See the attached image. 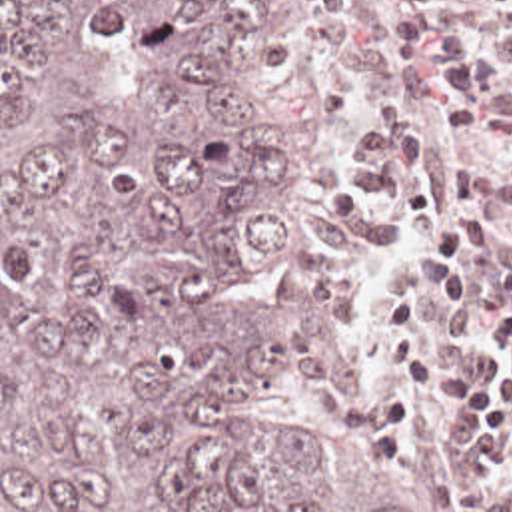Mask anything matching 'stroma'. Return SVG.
I'll return each instance as SVG.
<instances>
[{"label": "stroma", "instance_id": "obj_1", "mask_svg": "<svg viewBox=\"0 0 512 512\" xmlns=\"http://www.w3.org/2000/svg\"><path fill=\"white\" fill-rule=\"evenodd\" d=\"M345 1L325 0L323 5H319L293 27L239 53L245 71L265 85L273 107V143L275 153L285 163L289 173L291 213L297 227V249L277 273L261 279L247 291L239 293L235 299L247 301L271 313L273 297L283 281L311 271L349 313L365 347L371 369L385 380V404L381 418L363 428L349 430L393 474L409 484L425 512H461L453 492L429 482L417 466L413 450V398L401 386L383 355L373 345L357 303L331 255L319 197L309 175L299 119L289 97L287 63L335 29ZM241 422L255 428H277L299 422H321V418L313 414L303 394L301 378L295 374L275 378L259 386Z\"/></svg>", "mask_w": 512, "mask_h": 512}]
</instances>
